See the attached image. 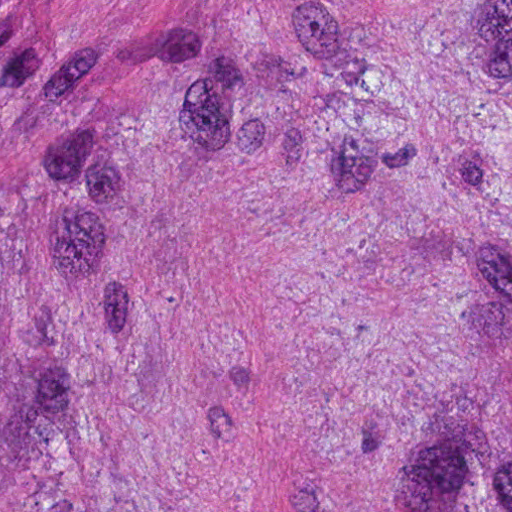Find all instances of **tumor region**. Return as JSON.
I'll return each mask as SVG.
<instances>
[{"mask_svg":"<svg viewBox=\"0 0 512 512\" xmlns=\"http://www.w3.org/2000/svg\"><path fill=\"white\" fill-rule=\"evenodd\" d=\"M0 512H512V4L70 110L0 49Z\"/></svg>","mask_w":512,"mask_h":512,"instance_id":"e687c5a6","label":"tumor region"}]
</instances>
